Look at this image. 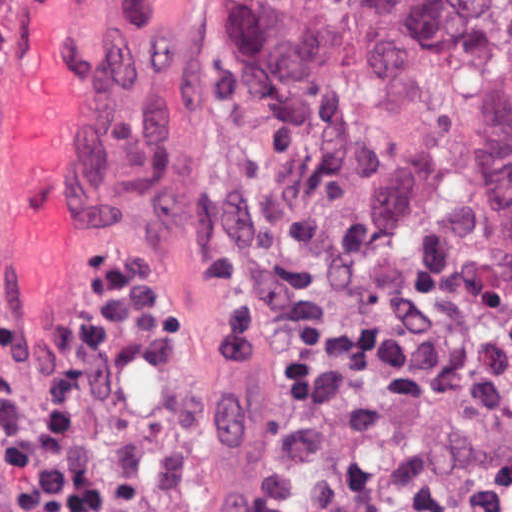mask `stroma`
<instances>
[{"mask_svg":"<svg viewBox=\"0 0 512 512\" xmlns=\"http://www.w3.org/2000/svg\"><path fill=\"white\" fill-rule=\"evenodd\" d=\"M221 1L512 0H0V328L17 309L44 355L116 255L152 280V311L168 312L188 373L235 431L276 387L239 357L214 281L248 266ZM0 512H19L1 435Z\"/></svg>","mask_w":512,"mask_h":512,"instance_id":"1","label":"stroma"}]
</instances>
